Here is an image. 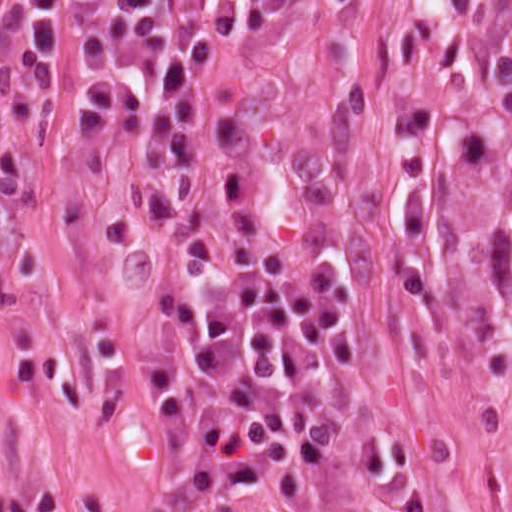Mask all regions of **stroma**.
I'll list each match as a JSON object with an SVG mask.
<instances>
[{"instance_id": "1", "label": "stroma", "mask_w": 512, "mask_h": 512, "mask_svg": "<svg viewBox=\"0 0 512 512\" xmlns=\"http://www.w3.org/2000/svg\"><path fill=\"white\" fill-rule=\"evenodd\" d=\"M0 202V512H512V0H241L202 88V151L258 245L329 284L351 369L322 424L238 488H198L144 431L180 327L136 289L138 132L26 86ZM1 93V82H0ZM125 349L107 426L89 329Z\"/></svg>"}]
</instances>
